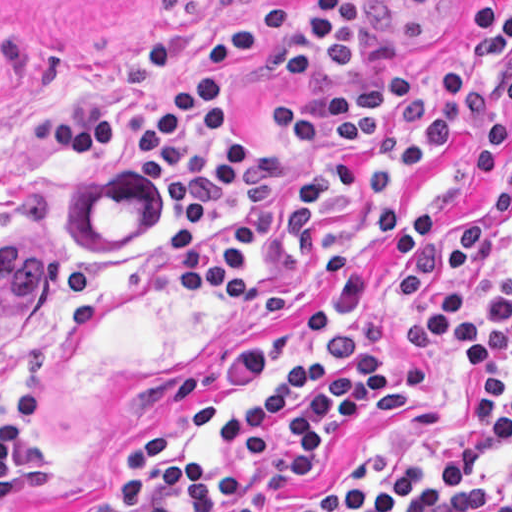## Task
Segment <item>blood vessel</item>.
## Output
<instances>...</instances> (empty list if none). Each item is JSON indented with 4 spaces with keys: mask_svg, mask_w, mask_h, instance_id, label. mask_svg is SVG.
<instances>
[{
    "mask_svg": "<svg viewBox=\"0 0 512 512\" xmlns=\"http://www.w3.org/2000/svg\"><path fill=\"white\" fill-rule=\"evenodd\" d=\"M409 4L428 11H458L474 0H406Z\"/></svg>",
    "mask_w": 512,
    "mask_h": 512,
    "instance_id": "obj_1",
    "label": "blood vessel"
}]
</instances>
